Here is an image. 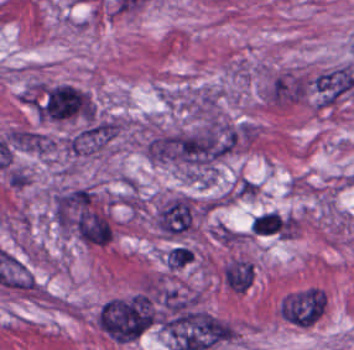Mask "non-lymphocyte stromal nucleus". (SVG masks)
Returning <instances> with one entry per match:
<instances>
[{"label":"non-lymphocyte stromal nucleus","instance_id":"obj_1","mask_svg":"<svg viewBox=\"0 0 354 350\" xmlns=\"http://www.w3.org/2000/svg\"><path fill=\"white\" fill-rule=\"evenodd\" d=\"M162 327L174 350H210L230 342V325L186 304L171 308L162 318Z\"/></svg>","mask_w":354,"mask_h":350},{"label":"non-lymphocyte stromal nucleus","instance_id":"obj_2","mask_svg":"<svg viewBox=\"0 0 354 350\" xmlns=\"http://www.w3.org/2000/svg\"><path fill=\"white\" fill-rule=\"evenodd\" d=\"M88 93L70 84L59 83L45 89L35 110L41 119H62L83 113Z\"/></svg>","mask_w":354,"mask_h":350},{"label":"non-lymphocyte stromal nucleus","instance_id":"obj_3","mask_svg":"<svg viewBox=\"0 0 354 350\" xmlns=\"http://www.w3.org/2000/svg\"><path fill=\"white\" fill-rule=\"evenodd\" d=\"M154 224L163 232L176 234L191 228L189 197L178 196L159 208Z\"/></svg>","mask_w":354,"mask_h":350},{"label":"non-lymphocyte stromal nucleus","instance_id":"obj_4","mask_svg":"<svg viewBox=\"0 0 354 350\" xmlns=\"http://www.w3.org/2000/svg\"><path fill=\"white\" fill-rule=\"evenodd\" d=\"M250 229L256 236L288 238L287 216L265 211L252 218Z\"/></svg>","mask_w":354,"mask_h":350},{"label":"non-lymphocyte stromal nucleus","instance_id":"obj_5","mask_svg":"<svg viewBox=\"0 0 354 350\" xmlns=\"http://www.w3.org/2000/svg\"><path fill=\"white\" fill-rule=\"evenodd\" d=\"M8 141L20 150L47 152L52 146V140L45 133L27 128H14Z\"/></svg>","mask_w":354,"mask_h":350},{"label":"non-lymphocyte stromal nucleus","instance_id":"obj_6","mask_svg":"<svg viewBox=\"0 0 354 350\" xmlns=\"http://www.w3.org/2000/svg\"><path fill=\"white\" fill-rule=\"evenodd\" d=\"M253 279L252 267L239 259H232L225 266V283L236 293H243Z\"/></svg>","mask_w":354,"mask_h":350},{"label":"non-lymphocyte stromal nucleus","instance_id":"obj_7","mask_svg":"<svg viewBox=\"0 0 354 350\" xmlns=\"http://www.w3.org/2000/svg\"><path fill=\"white\" fill-rule=\"evenodd\" d=\"M194 252L187 246L175 244L167 253L164 262L173 268L185 267L192 259Z\"/></svg>","mask_w":354,"mask_h":350}]
</instances>
